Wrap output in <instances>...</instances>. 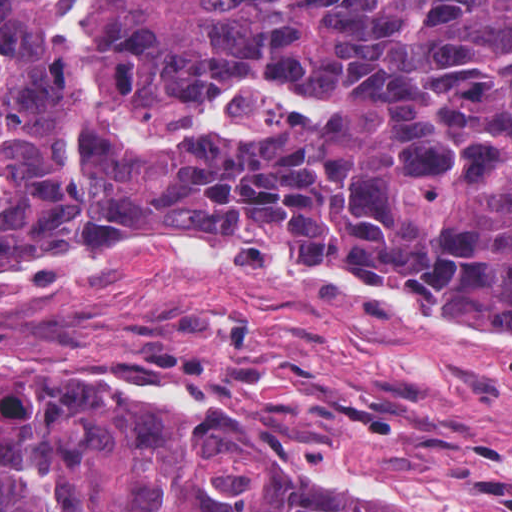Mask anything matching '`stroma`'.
Listing matches in <instances>:
<instances>
[{
  "label": "stroma",
  "instance_id": "35a3bbf8",
  "mask_svg": "<svg viewBox=\"0 0 512 512\" xmlns=\"http://www.w3.org/2000/svg\"><path fill=\"white\" fill-rule=\"evenodd\" d=\"M213 249L233 259L259 254ZM61 250L46 247L17 264ZM289 263L396 285L426 310L512 334L402 284L324 262ZM98 351L128 371L219 383L297 449L402 474L470 512H512V352L424 339L356 301L159 260L105 265L76 282L0 283V371Z\"/></svg>",
  "mask_w": 512,
  "mask_h": 512
}]
</instances>
